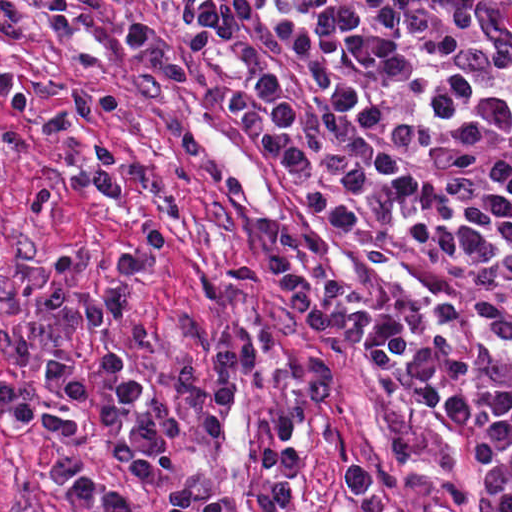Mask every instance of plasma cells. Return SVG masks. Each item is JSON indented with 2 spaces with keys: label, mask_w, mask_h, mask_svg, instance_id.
Here are the masks:
<instances>
[{
  "label": "plasma cells",
  "mask_w": 512,
  "mask_h": 512,
  "mask_svg": "<svg viewBox=\"0 0 512 512\" xmlns=\"http://www.w3.org/2000/svg\"><path fill=\"white\" fill-rule=\"evenodd\" d=\"M177 21L189 55L204 47L225 48L240 37L242 10L231 0H176ZM32 6L24 0H0V40L30 38ZM124 38L136 58L129 76L134 95L152 105L169 102L173 90L194 77L163 24L140 16ZM54 98L60 107L41 115L35 126L45 136L71 145L63 176L34 188L25 216L41 218L75 192L88 191L114 201L146 191L150 181L140 170L125 173L122 153L105 138L89 133L92 122L124 107L112 91H82L30 75L0 76V103L20 116L35 100ZM18 132L0 134V173L31 153ZM2 220L0 217V226ZM268 267L290 310L325 333L346 331L372 344L368 368L388 405L392 433L390 469H404L425 454V441L408 401L436 410L465 440L484 468L483 496L472 506L453 481L441 484L437 512H512V186L497 185L437 233L489 255L479 269L459 271L422 262L412 269L427 289V302L413 312L377 314L333 279L326 240L296 221L271 217L254 227ZM175 238L165 220L147 218L131 249L114 254L106 288L65 280L58 263L36 256L20 275L23 299L39 309L9 325V354L17 369L32 366L35 339L62 343L82 330L106 334L126 325L137 302L139 280L154 272ZM277 329L269 326L222 337L212 348L214 376L190 362L176 363L172 380L182 405L202 418L180 417L159 396H149L131 358L122 350L105 351L98 364L83 371L58 354L44 359V373L69 409L25 396L0 385V413L23 432L52 429L63 437L83 438L88 428L109 442L127 475L164 512H288L303 469V416L286 406L268 424L256 455L274 492L239 502L219 499L202 488L172 480L165 468V439L216 441L238 395V379L251 387H288L310 404L334 392L328 361L312 357L309 380L299 382L289 367L270 364ZM51 480L84 512H138L105 485L76 453L49 452ZM347 484L359 512H405L376 477L358 465L346 469Z\"/></svg>",
  "instance_id": "obj_1"
}]
</instances>
